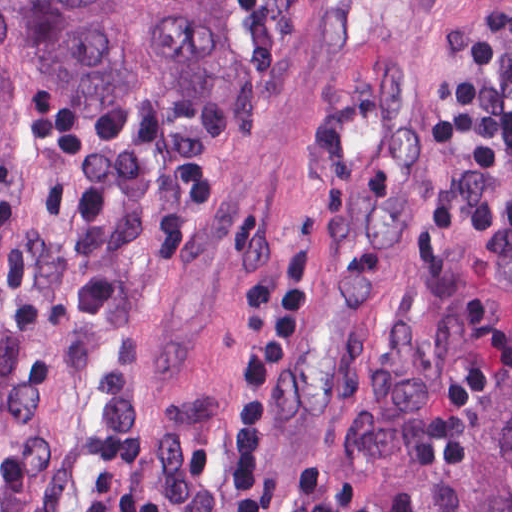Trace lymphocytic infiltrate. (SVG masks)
<instances>
[{
	"instance_id": "1",
	"label": "lymphocytic infiltrate",
	"mask_w": 512,
	"mask_h": 512,
	"mask_svg": "<svg viewBox=\"0 0 512 512\" xmlns=\"http://www.w3.org/2000/svg\"><path fill=\"white\" fill-rule=\"evenodd\" d=\"M470 164L512 189V4L486 41L448 125ZM315 266L311 208H297L284 240L274 312L240 356L231 383L239 461L231 512H373L360 491L316 463H289L273 483L265 474V406L278 362L306 308ZM76 512H160L158 498L122 477L84 481Z\"/></svg>"
}]
</instances>
